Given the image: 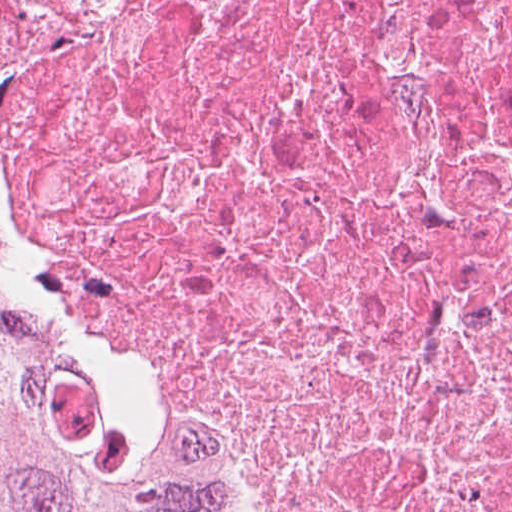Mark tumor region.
<instances>
[{"mask_svg": "<svg viewBox=\"0 0 512 512\" xmlns=\"http://www.w3.org/2000/svg\"><path fill=\"white\" fill-rule=\"evenodd\" d=\"M0 512H221L28 309L1 233Z\"/></svg>", "mask_w": 512, "mask_h": 512, "instance_id": "obj_1", "label": "tumor region"}]
</instances>
